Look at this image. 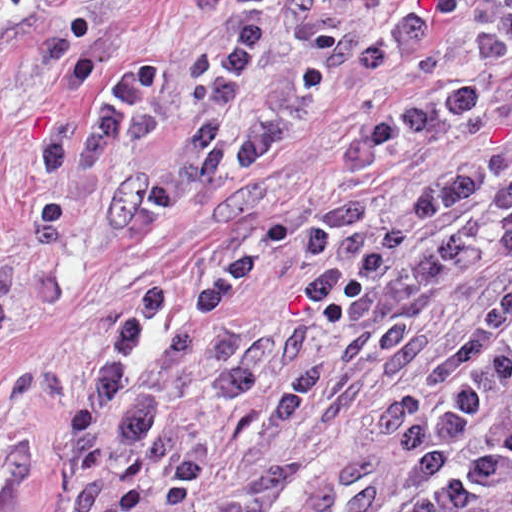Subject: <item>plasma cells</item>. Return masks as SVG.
Returning a JSON list of instances; mask_svg holds the SVG:
<instances>
[{"instance_id": "obj_1", "label": "plasma cells", "mask_w": 512, "mask_h": 512, "mask_svg": "<svg viewBox=\"0 0 512 512\" xmlns=\"http://www.w3.org/2000/svg\"><path fill=\"white\" fill-rule=\"evenodd\" d=\"M125 2L14 0L1 36V512L34 465L13 347L76 276L164 238L293 146L352 78L370 115L337 162L378 177L480 132L512 69V0H241L222 38L175 60L131 31ZM484 212L512 258L511 150L475 152L369 220L318 214L296 294L341 331L278 387L272 437L328 432L372 398L473 265ZM284 236L280 222L236 231L98 322L82 378L62 382L61 512L190 501L207 440L167 416L162 383L202 350L216 400L241 407L317 337L236 317ZM207 512H512V283L447 340L362 457L273 468Z\"/></svg>"}]
</instances>
